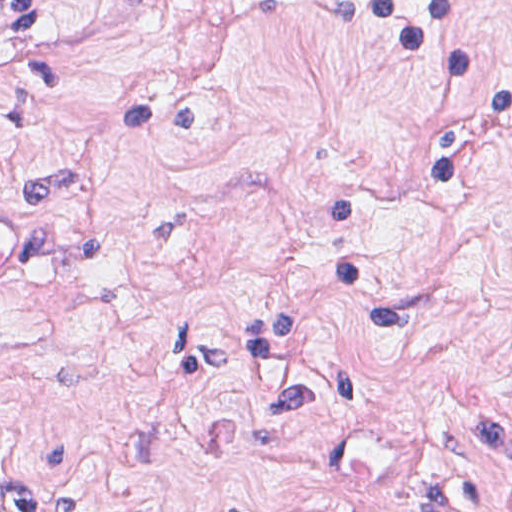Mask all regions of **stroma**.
<instances>
[{
    "label": "stroma",
    "instance_id": "stroma-1",
    "mask_svg": "<svg viewBox=\"0 0 512 512\" xmlns=\"http://www.w3.org/2000/svg\"><path fill=\"white\" fill-rule=\"evenodd\" d=\"M475 1L512 79V0ZM440 104L389 30L320 0L0 26V204L39 230L35 281L0 293V485L42 512H512V147L350 214L407 323L348 327L316 277L321 185L431 155Z\"/></svg>",
    "mask_w": 512,
    "mask_h": 512
}]
</instances>
